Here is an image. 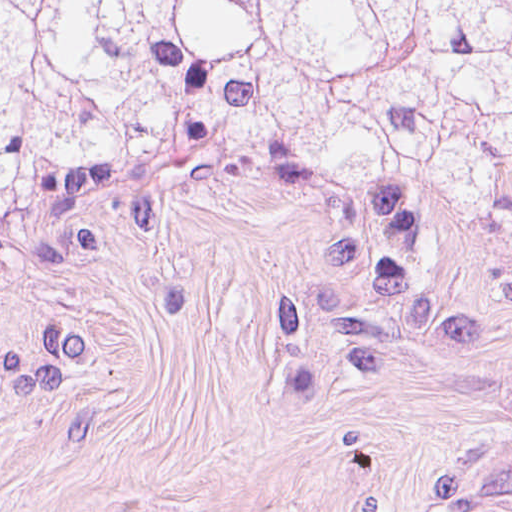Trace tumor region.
Returning a JSON list of instances; mask_svg holds the SVG:
<instances>
[{
  "label": "tumor region",
  "instance_id": "tumor-region-1",
  "mask_svg": "<svg viewBox=\"0 0 512 512\" xmlns=\"http://www.w3.org/2000/svg\"><path fill=\"white\" fill-rule=\"evenodd\" d=\"M191 137L512 228V0H0V209Z\"/></svg>",
  "mask_w": 512,
  "mask_h": 512
}]
</instances>
